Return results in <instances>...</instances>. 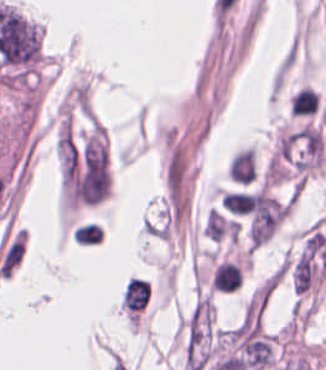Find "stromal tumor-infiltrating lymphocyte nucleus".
Masks as SVG:
<instances>
[{"label":"stromal tumor-infiltrating lymphocyte nucleus","mask_w":326,"mask_h":370,"mask_svg":"<svg viewBox=\"0 0 326 370\" xmlns=\"http://www.w3.org/2000/svg\"><path fill=\"white\" fill-rule=\"evenodd\" d=\"M242 284V271L231 261L217 265L212 275L211 287L223 292H233Z\"/></svg>","instance_id":"1"},{"label":"stromal tumor-infiltrating lymphocyte nucleus","mask_w":326,"mask_h":370,"mask_svg":"<svg viewBox=\"0 0 326 370\" xmlns=\"http://www.w3.org/2000/svg\"><path fill=\"white\" fill-rule=\"evenodd\" d=\"M319 103L316 90L301 86L289 97V112L295 115L314 114Z\"/></svg>","instance_id":"2"},{"label":"stromal tumor-infiltrating lymphocyte nucleus","mask_w":326,"mask_h":370,"mask_svg":"<svg viewBox=\"0 0 326 370\" xmlns=\"http://www.w3.org/2000/svg\"><path fill=\"white\" fill-rule=\"evenodd\" d=\"M253 193L245 191H226L221 203L232 215H248Z\"/></svg>","instance_id":"3"}]
</instances>
